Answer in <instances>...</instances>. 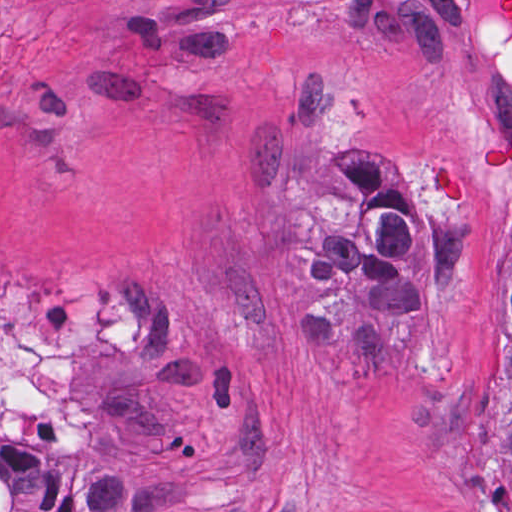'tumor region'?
<instances>
[{
	"instance_id": "obj_1",
	"label": "tumor region",
	"mask_w": 512,
	"mask_h": 512,
	"mask_svg": "<svg viewBox=\"0 0 512 512\" xmlns=\"http://www.w3.org/2000/svg\"><path fill=\"white\" fill-rule=\"evenodd\" d=\"M494 39L512 60V0L495 3ZM512 173V141L477 156L476 188ZM452 204H469L450 166L427 180ZM297 211L306 220L304 279L312 307L302 314L300 344L343 357L363 389L394 383L406 338L426 303L452 308L465 300L471 227L425 215L414 188L390 163L360 143L344 145L336 174L298 182ZM509 239L512 249V217ZM493 443L512 492V307L497 368Z\"/></svg>"
}]
</instances>
